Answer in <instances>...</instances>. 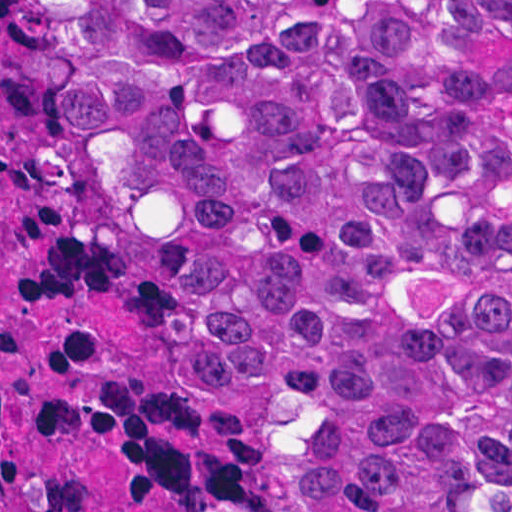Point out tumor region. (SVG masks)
<instances>
[{"mask_svg":"<svg viewBox=\"0 0 512 512\" xmlns=\"http://www.w3.org/2000/svg\"><path fill=\"white\" fill-rule=\"evenodd\" d=\"M27 1L315 512H512V0Z\"/></svg>","mask_w":512,"mask_h":512,"instance_id":"1","label":"tumor region"}]
</instances>
